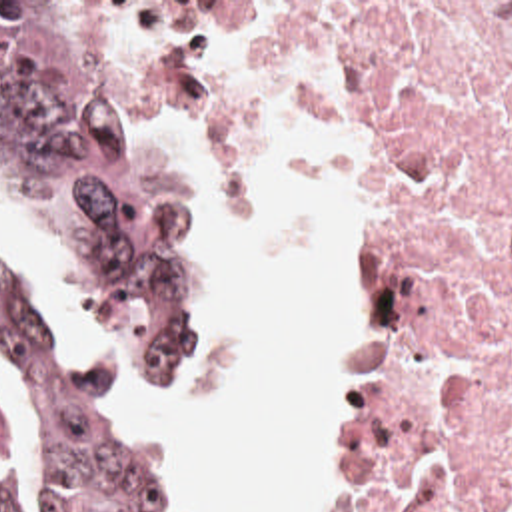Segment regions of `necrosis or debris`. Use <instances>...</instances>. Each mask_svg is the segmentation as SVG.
I'll use <instances>...</instances> for the list:
<instances>
[{
	"mask_svg": "<svg viewBox=\"0 0 512 512\" xmlns=\"http://www.w3.org/2000/svg\"><path fill=\"white\" fill-rule=\"evenodd\" d=\"M160 34L370 150L372 512H512V2H160Z\"/></svg>",
	"mask_w": 512,
	"mask_h": 512,
	"instance_id": "1",
	"label": "necrosis or debris"
}]
</instances>
